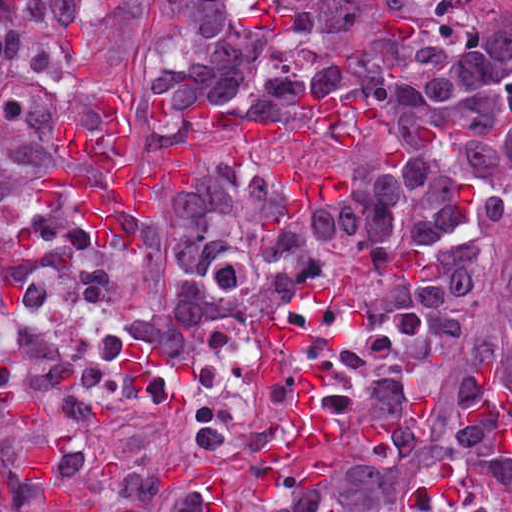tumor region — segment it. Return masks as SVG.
I'll list each match as a JSON object with an SVG mask.
<instances>
[{
  "mask_svg": "<svg viewBox=\"0 0 512 512\" xmlns=\"http://www.w3.org/2000/svg\"><path fill=\"white\" fill-rule=\"evenodd\" d=\"M479 0H0V262L105 266L149 356L322 235L428 246L512 217V27ZM123 98L195 193L108 199L73 111ZM43 174L50 210L31 189ZM166 259L184 276L145 270Z\"/></svg>",
  "mask_w": 512,
  "mask_h": 512,
  "instance_id": "e687c5a6",
  "label": "tumor region"
}]
</instances>
